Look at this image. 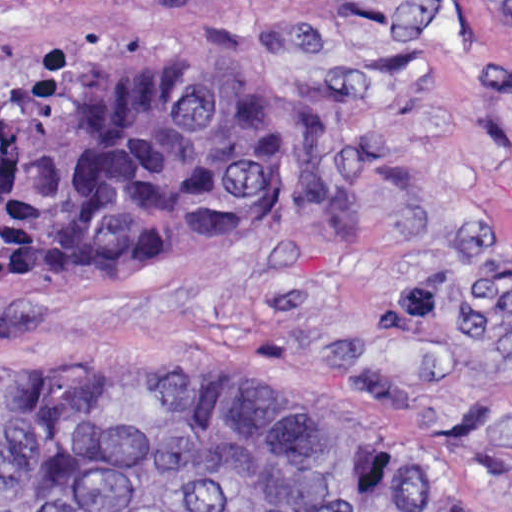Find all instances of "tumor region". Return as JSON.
I'll use <instances>...</instances> for the list:
<instances>
[{"instance_id": "tumor-region-1", "label": "tumor region", "mask_w": 512, "mask_h": 512, "mask_svg": "<svg viewBox=\"0 0 512 512\" xmlns=\"http://www.w3.org/2000/svg\"><path fill=\"white\" fill-rule=\"evenodd\" d=\"M178 44L110 51L0 98V293L255 234L287 143L274 95ZM0 512H464L299 397L105 355L0 360Z\"/></svg>"}]
</instances>
